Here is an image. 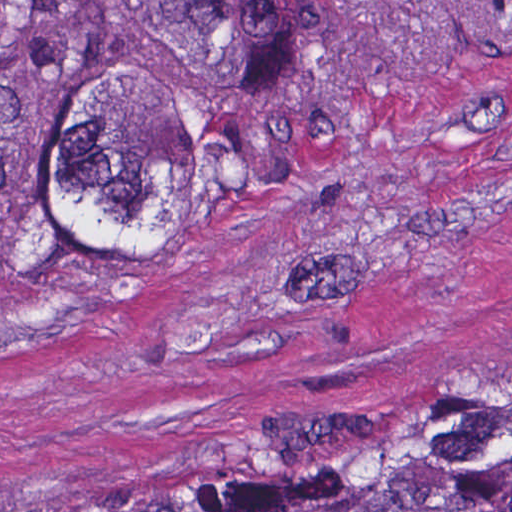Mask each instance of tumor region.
Here are the masks:
<instances>
[{"label": "tumor region", "mask_w": 512, "mask_h": 512, "mask_svg": "<svg viewBox=\"0 0 512 512\" xmlns=\"http://www.w3.org/2000/svg\"><path fill=\"white\" fill-rule=\"evenodd\" d=\"M348 114L337 0H0V291L289 201ZM134 512H512V393Z\"/></svg>", "instance_id": "1"}]
</instances>
